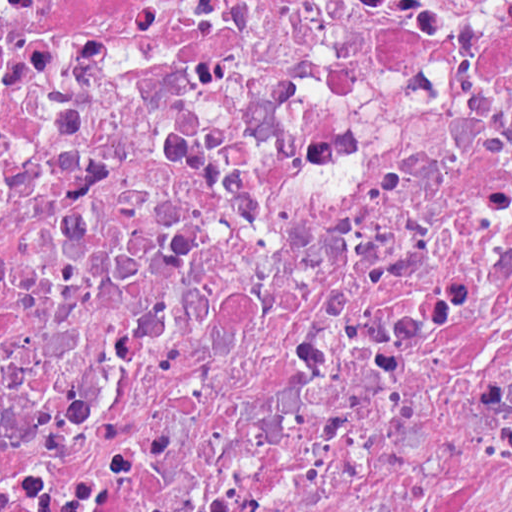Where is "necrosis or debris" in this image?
I'll return each instance as SVG.
<instances>
[{
  "label": "necrosis or debris",
  "instance_id": "4bbe7bcc",
  "mask_svg": "<svg viewBox=\"0 0 512 512\" xmlns=\"http://www.w3.org/2000/svg\"><path fill=\"white\" fill-rule=\"evenodd\" d=\"M0 512H512V1H0Z\"/></svg>",
  "mask_w": 512,
  "mask_h": 512
}]
</instances>
